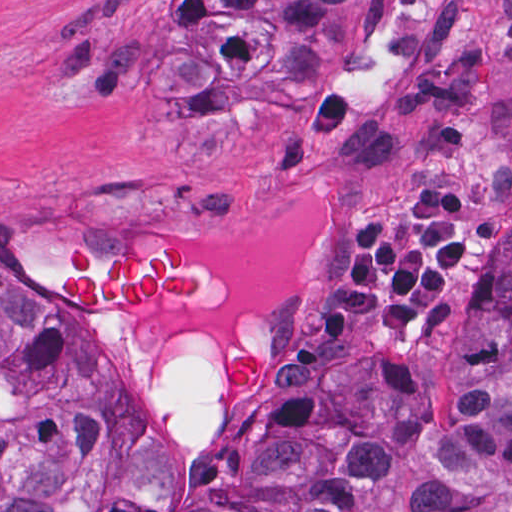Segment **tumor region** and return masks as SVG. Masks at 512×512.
I'll list each match as a JSON object with an SVG mask.
<instances>
[{
  "label": "tumor region",
  "instance_id": "1",
  "mask_svg": "<svg viewBox=\"0 0 512 512\" xmlns=\"http://www.w3.org/2000/svg\"><path fill=\"white\" fill-rule=\"evenodd\" d=\"M379 1H89L47 40L49 72L76 94H143L203 155L242 122L304 170L325 70L377 20ZM486 222L480 165H454L375 214L348 206L333 262L291 303L290 352L359 322L405 346L455 329V279ZM54 295L79 310L176 321L206 305L188 235L165 226L110 253L57 239ZM216 344L182 325L162 374L167 435L211 430ZM267 376L245 336L225 342L218 385ZM156 430L98 349L0 276V512H151ZM175 512H512V239L480 274L446 370L388 382L370 353L335 358L318 387L237 413L213 437Z\"/></svg>",
  "mask_w": 512,
  "mask_h": 512
}]
</instances>
